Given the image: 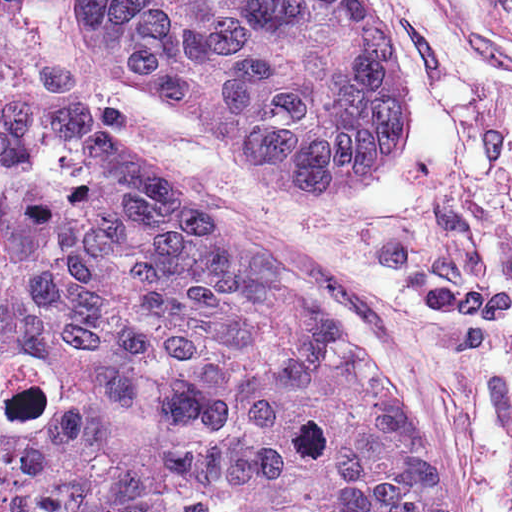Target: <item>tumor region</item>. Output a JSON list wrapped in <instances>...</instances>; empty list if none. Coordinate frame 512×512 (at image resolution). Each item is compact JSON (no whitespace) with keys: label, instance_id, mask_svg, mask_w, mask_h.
<instances>
[{"label":"tumor region","instance_id":"tumor-region-1","mask_svg":"<svg viewBox=\"0 0 512 512\" xmlns=\"http://www.w3.org/2000/svg\"><path fill=\"white\" fill-rule=\"evenodd\" d=\"M83 9L118 73L291 207L348 205L408 149L373 0ZM0 512L449 510L342 328L158 169L0 95Z\"/></svg>","mask_w":512,"mask_h":512}]
</instances>
